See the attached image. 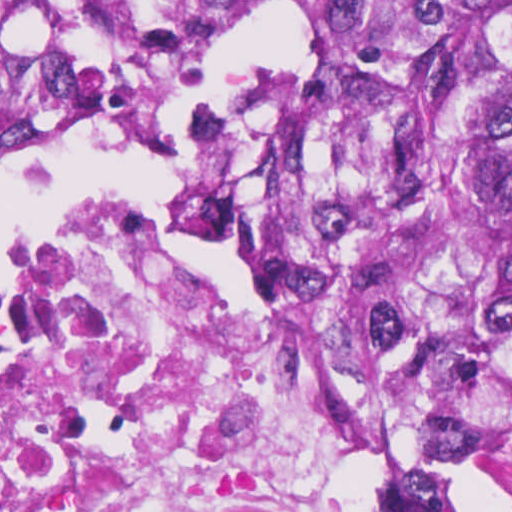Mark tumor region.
Instances as JSON below:
<instances>
[{
	"mask_svg": "<svg viewBox=\"0 0 512 512\" xmlns=\"http://www.w3.org/2000/svg\"><path fill=\"white\" fill-rule=\"evenodd\" d=\"M83 1H0V157L58 142L99 86ZM296 270L406 458L374 512H466L512 416V1L350 4L309 67Z\"/></svg>",
	"mask_w": 512,
	"mask_h": 512,
	"instance_id": "obj_1",
	"label": "tumor region"
}]
</instances>
